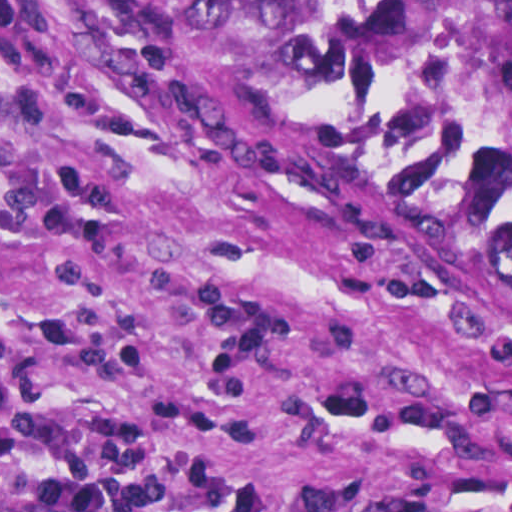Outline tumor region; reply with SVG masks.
I'll return each instance as SVG.
<instances>
[{
	"label": "tumor region",
	"mask_w": 512,
	"mask_h": 512,
	"mask_svg": "<svg viewBox=\"0 0 512 512\" xmlns=\"http://www.w3.org/2000/svg\"><path fill=\"white\" fill-rule=\"evenodd\" d=\"M301 145L371 156L512 277V169L464 116L469 77L512 82V0H69ZM1 512H126L78 469L1 470Z\"/></svg>",
	"instance_id": "obj_1"
}]
</instances>
